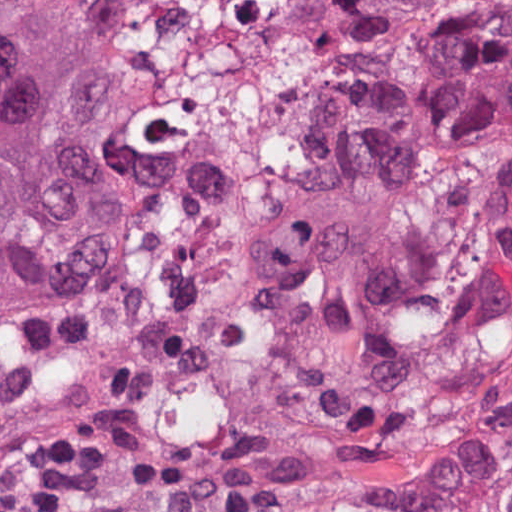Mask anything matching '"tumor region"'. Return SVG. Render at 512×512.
<instances>
[{
    "label": "tumor region",
    "mask_w": 512,
    "mask_h": 512,
    "mask_svg": "<svg viewBox=\"0 0 512 512\" xmlns=\"http://www.w3.org/2000/svg\"><path fill=\"white\" fill-rule=\"evenodd\" d=\"M142 132L90 1L0 29V300L108 276ZM277 205L227 512H512V0H354Z\"/></svg>",
    "instance_id": "1"
}]
</instances>
